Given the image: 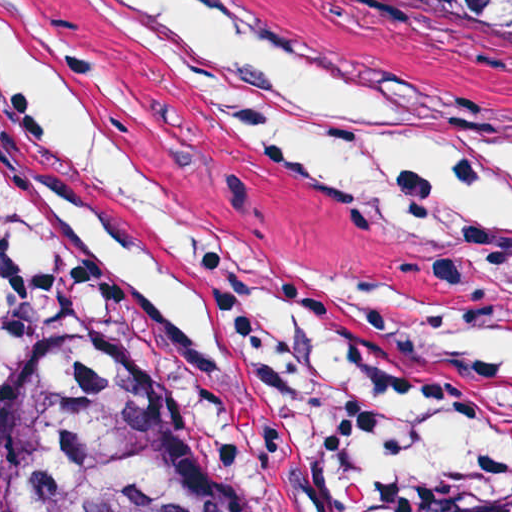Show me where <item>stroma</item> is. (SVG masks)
<instances>
[{"mask_svg":"<svg viewBox=\"0 0 512 512\" xmlns=\"http://www.w3.org/2000/svg\"><path fill=\"white\" fill-rule=\"evenodd\" d=\"M228 1L278 38L464 104L512 133V93L408 0ZM72 77L140 186L110 197L83 181L0 72L6 269L104 274L60 236L37 191L121 249H137V191H171L200 222L199 321L214 353L192 354L150 299L106 274L116 307L92 344L153 351L233 419L251 454V512H414L428 494L374 489L259 352L290 332L392 305L413 283L402 237L357 190L123 43H72Z\"/></svg>","mask_w":512,"mask_h":512,"instance_id":"35a3bbf8","label":"stroma"}]
</instances>
